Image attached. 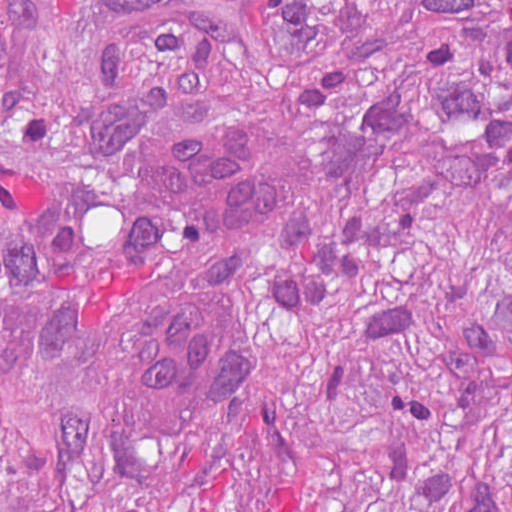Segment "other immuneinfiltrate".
Segmentation results:
<instances>
[{"mask_svg": "<svg viewBox=\"0 0 512 512\" xmlns=\"http://www.w3.org/2000/svg\"><path fill=\"white\" fill-rule=\"evenodd\" d=\"M285 149L247 114L208 120L159 154L155 203L194 243L248 245L277 224ZM207 291L177 293L142 325L129 356L133 396L172 422L219 415L245 371V331Z\"/></svg>", "mask_w": 512, "mask_h": 512, "instance_id": "bc1004c8", "label": "other immune infiltrate"}]
</instances>
